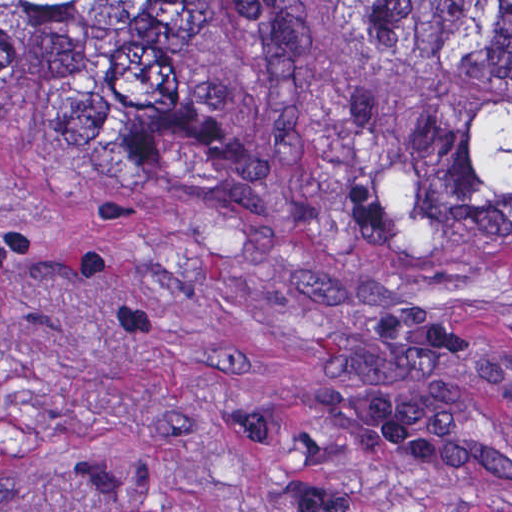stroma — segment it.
Instances as JSON below:
<instances>
[{"instance_id": "obj_1", "label": "stroma", "mask_w": 512, "mask_h": 512, "mask_svg": "<svg viewBox=\"0 0 512 512\" xmlns=\"http://www.w3.org/2000/svg\"><path fill=\"white\" fill-rule=\"evenodd\" d=\"M228 176L0 128V512H512V252L360 0H142Z\"/></svg>"}]
</instances>
